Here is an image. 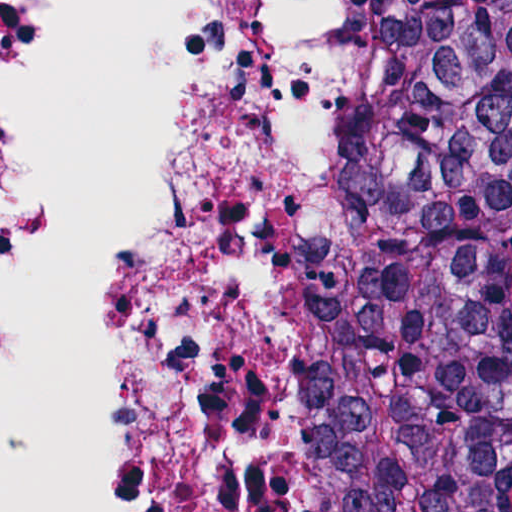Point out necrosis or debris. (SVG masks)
<instances>
[{"label": "necrosis or debris", "mask_w": 512, "mask_h": 512, "mask_svg": "<svg viewBox=\"0 0 512 512\" xmlns=\"http://www.w3.org/2000/svg\"><path fill=\"white\" fill-rule=\"evenodd\" d=\"M376 89L377 0H215L126 348L114 512H302L290 284ZM21 100L17 0H0V290Z\"/></svg>", "instance_id": "4bbe7bcc"}]
</instances>
